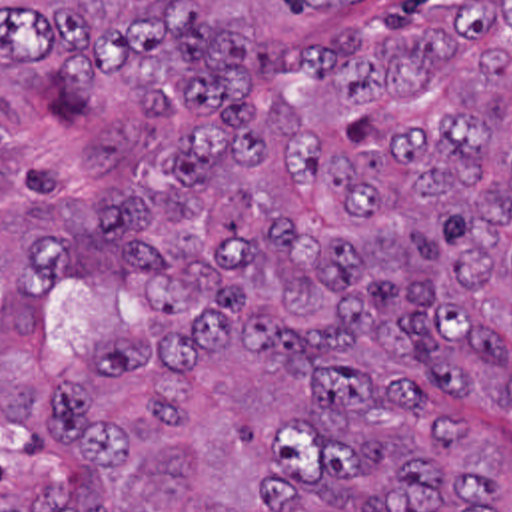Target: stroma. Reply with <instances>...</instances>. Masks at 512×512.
<instances>
[{"label":"stroma","instance_id":"1","mask_svg":"<svg viewBox=\"0 0 512 512\" xmlns=\"http://www.w3.org/2000/svg\"><path fill=\"white\" fill-rule=\"evenodd\" d=\"M467 426L475 461L487 481L503 489V512H512V418L495 410H453Z\"/></svg>","mask_w":512,"mask_h":512}]
</instances>
